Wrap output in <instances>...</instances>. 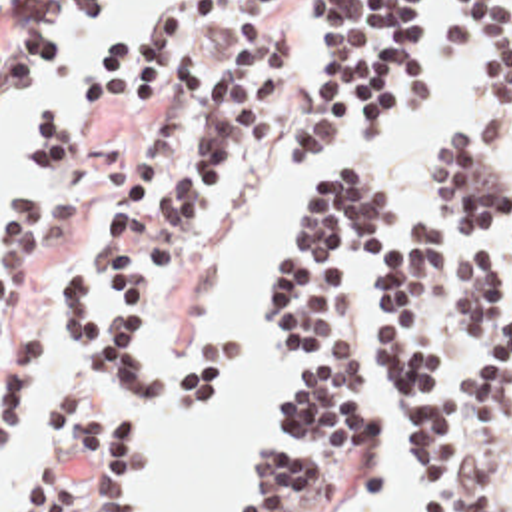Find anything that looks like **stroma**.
I'll return each mask as SVG.
<instances>
[{
	"instance_id": "obj_1",
	"label": "stroma",
	"mask_w": 512,
	"mask_h": 512,
	"mask_svg": "<svg viewBox=\"0 0 512 512\" xmlns=\"http://www.w3.org/2000/svg\"><path fill=\"white\" fill-rule=\"evenodd\" d=\"M18 0H0V512H12L16 494L20 490L22 472L26 464V456L32 448L34 430H36V413L44 397L56 385L66 361L72 357V349L66 347L60 339H56L48 325V297L66 267L72 265H88L94 257L92 237L100 221L104 219L106 211L112 203L122 195L132 169L142 153V133L146 125L152 121L158 109V101L140 117L112 123L104 121L98 115V107L90 103H82L86 109L82 121L70 119L62 113H54L66 119L82 145V171L74 185V205H76V229L70 237L42 255L32 287H30V319L32 331L38 351V377L36 387L32 389L24 409L16 417V421L2 434V213L6 211L12 197L20 195L24 187L30 183L34 175V167L30 161L28 177L24 185H14L4 163H2V113L8 99L22 87H8L2 85V35L6 31L8 17ZM453 0H425V41L427 49L439 69V101L435 107L425 109L405 121H399L389 135V139L377 147L365 141L359 125V113L353 115L341 135V139L333 145V149L315 163L305 165V189L301 207L297 209L292 221V229L288 237L278 245L272 261H270V283L264 303V353L266 361L272 367V415H274V397L276 391L286 387L294 377L292 363L288 361L286 353L276 347L272 339V269L278 255L288 245L297 223L301 221L303 207L307 201L309 187L339 165H359L367 171L383 177L389 181L397 195H399V213L401 215H415L425 209V151L431 141L445 129L461 123L465 117L471 115L477 99H479V61L473 49L447 53L439 43L437 25L445 11L449 9ZM94 13L86 27L80 29H62L56 37V59L50 63L46 71L60 65L66 57V39L80 35L88 29L100 27V13L104 0H90ZM150 15V13H148ZM144 17L126 21L116 27L110 39H118L130 33ZM276 33L288 35L292 45V113L296 109L297 95L311 71L313 55L317 51V1L315 0H286L280 15L276 17L274 25ZM108 39V41H110ZM44 71V73H46ZM42 73V75H44ZM36 81V79H34ZM50 115V113H48ZM284 133L264 149L256 159H252L246 167L218 183L212 201V215L206 237L200 249L176 271L170 275L154 311L152 321V357L154 361H170L184 357L190 347L206 339L208 335H184L176 343L164 347L162 339V317L174 299L194 281L198 275L204 257L208 253L210 243L218 235L220 219H222V201L226 195L244 185L258 169L276 171V173H290L301 167H286L282 161V143ZM503 179L512 189V133L507 143V159L503 163ZM505 267V309H507V287L511 279V251L503 249L501 245L493 247ZM445 259H451V251L445 247ZM383 299V265L379 257H363L353 275V305L355 315L361 329V399L363 405L371 411L375 423L383 428L379 438V478L373 492L367 500L357 506L353 512H407V496H409V458L407 452L393 430V411H391V391L387 387L385 373L379 365V347L375 341V317L379 313ZM236 339L242 349V367L246 363V341L238 333H228ZM475 355V345H463L455 351L453 365H451V397L457 413V448L467 450L473 454L481 466L489 472L495 484L497 504L493 512H512V444L501 440V423L509 415L512 407V385L503 395L497 415L489 428L481 432H467V413L463 405V385L461 377ZM242 373V371H240ZM238 385V381H236ZM236 385L222 395L200 419L186 423L176 419L194 430L206 426L210 415L218 411L224 403H228L236 391ZM118 409L130 413L140 421L144 428V468L138 484V512H152V484L156 480V462L150 448L148 428L146 421L136 405L142 397L132 395L124 389H118L114 397ZM166 413V411H164ZM170 415V413H166ZM172 417V415H170ZM288 442L278 426L276 436L268 444H284ZM262 450V448H260ZM258 450V452H260ZM244 486V484H242ZM242 490V488H240ZM238 498L236 496L232 512H238Z\"/></svg>"
}]
</instances>
